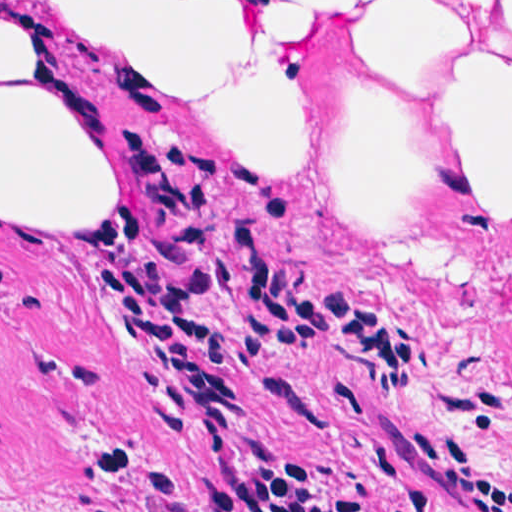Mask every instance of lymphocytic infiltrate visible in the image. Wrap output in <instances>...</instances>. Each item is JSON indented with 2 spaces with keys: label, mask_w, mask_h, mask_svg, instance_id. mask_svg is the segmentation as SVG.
<instances>
[{
  "label": "lymphocytic infiltrate",
  "mask_w": 512,
  "mask_h": 512,
  "mask_svg": "<svg viewBox=\"0 0 512 512\" xmlns=\"http://www.w3.org/2000/svg\"><path fill=\"white\" fill-rule=\"evenodd\" d=\"M149 142L140 176L95 247L118 255V298L110 307L121 324L123 356L146 365L136 378L140 397L174 441L192 427L199 431L210 471L209 491L198 504L177 473L161 470L149 512H365L291 455L239 464L233 430L251 413L250 404L235 393L224 345L189 312L202 298L199 284L188 279L175 292L148 246L144 220L164 219L179 248L237 293L254 357L331 350L393 395H407L423 360L419 342L318 278L270 266L259 225L244 226L238 249L225 259L216 216L220 195L240 196L285 224L290 203L225 155L197 149L152 153ZM405 438L421 460L458 485L467 512H512V476L475 431L411 423ZM111 447L127 466L129 449L112 441ZM100 512L127 511L115 496Z\"/></svg>",
  "instance_id": "obj_1"
}]
</instances>
